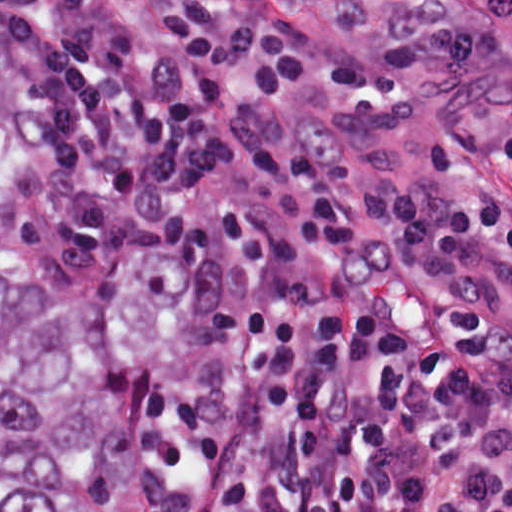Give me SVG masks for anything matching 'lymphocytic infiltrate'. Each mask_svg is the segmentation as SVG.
Masks as SVG:
<instances>
[{
    "instance_id": "obj_1",
    "label": "lymphocytic infiltrate",
    "mask_w": 512,
    "mask_h": 512,
    "mask_svg": "<svg viewBox=\"0 0 512 512\" xmlns=\"http://www.w3.org/2000/svg\"><path fill=\"white\" fill-rule=\"evenodd\" d=\"M160 23L137 54L88 0H0L33 268L185 262L164 512H512V54L337 62L210 1Z\"/></svg>"
}]
</instances>
